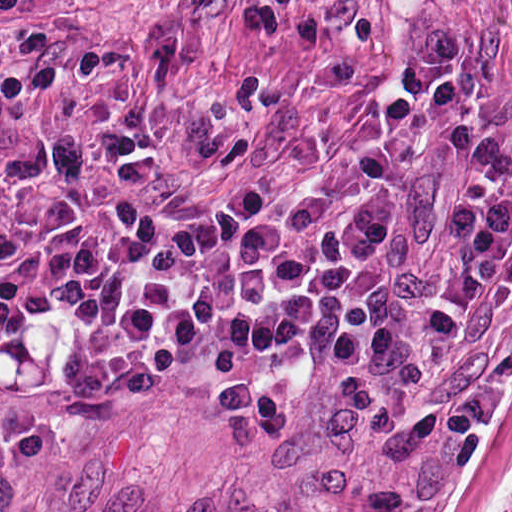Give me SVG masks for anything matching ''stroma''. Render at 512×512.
Here are the masks:
<instances>
[{
    "label": "stroma",
    "instance_id": "1",
    "mask_svg": "<svg viewBox=\"0 0 512 512\" xmlns=\"http://www.w3.org/2000/svg\"><path fill=\"white\" fill-rule=\"evenodd\" d=\"M248 0H0V264L58 194L124 191L134 295L0 367V512H82Z\"/></svg>",
    "mask_w": 512,
    "mask_h": 512
}]
</instances>
